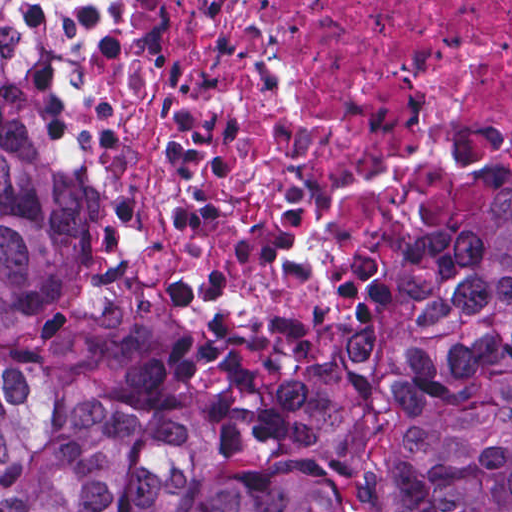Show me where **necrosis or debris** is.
<instances>
[{"label": "necrosis or debris", "instance_id": "obj_1", "mask_svg": "<svg viewBox=\"0 0 512 512\" xmlns=\"http://www.w3.org/2000/svg\"><path fill=\"white\" fill-rule=\"evenodd\" d=\"M119 24L96 157L144 247L204 290L269 283L336 228L331 290L396 259L413 217L512 139V0H66Z\"/></svg>", "mask_w": 512, "mask_h": 512}]
</instances>
